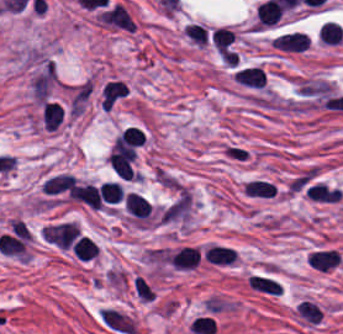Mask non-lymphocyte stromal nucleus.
<instances>
[{
    "mask_svg": "<svg viewBox=\"0 0 343 334\" xmlns=\"http://www.w3.org/2000/svg\"><path fill=\"white\" fill-rule=\"evenodd\" d=\"M97 315L101 323L122 334H133L135 331L132 319L117 310L101 307L97 310Z\"/></svg>",
    "mask_w": 343,
    "mask_h": 334,
    "instance_id": "1",
    "label": "non-lymphocyte stromal nucleus"
},
{
    "mask_svg": "<svg viewBox=\"0 0 343 334\" xmlns=\"http://www.w3.org/2000/svg\"><path fill=\"white\" fill-rule=\"evenodd\" d=\"M247 286L254 290L266 293H280V288L277 281L267 277L256 274H249L245 280Z\"/></svg>",
    "mask_w": 343,
    "mask_h": 334,
    "instance_id": "2",
    "label": "non-lymphocyte stromal nucleus"
}]
</instances>
